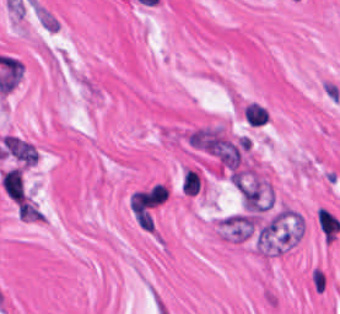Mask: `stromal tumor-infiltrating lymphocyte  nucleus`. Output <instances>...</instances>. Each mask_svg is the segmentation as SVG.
<instances>
[{
	"label": "stromal tumor-infiltrating lymphocyte nucleus",
	"instance_id": "stromal-tumor-infiltrating-lymphocyte-nucleus-1",
	"mask_svg": "<svg viewBox=\"0 0 340 314\" xmlns=\"http://www.w3.org/2000/svg\"><path fill=\"white\" fill-rule=\"evenodd\" d=\"M0 186L7 199L17 201L27 195L23 171L17 164L7 167L1 172Z\"/></svg>",
	"mask_w": 340,
	"mask_h": 314
},
{
	"label": "stromal tumor-infiltrating lymphocyte nucleus",
	"instance_id": "stromal-tumor-infiltrating-lymphocyte-nucleus-2",
	"mask_svg": "<svg viewBox=\"0 0 340 314\" xmlns=\"http://www.w3.org/2000/svg\"><path fill=\"white\" fill-rule=\"evenodd\" d=\"M317 222L324 240L331 242L339 228L340 222L320 207L317 210Z\"/></svg>",
	"mask_w": 340,
	"mask_h": 314
},
{
	"label": "stromal tumor-infiltrating lymphocyte nucleus",
	"instance_id": "stromal-tumor-infiltrating-lymphocyte-nucleus-3",
	"mask_svg": "<svg viewBox=\"0 0 340 314\" xmlns=\"http://www.w3.org/2000/svg\"><path fill=\"white\" fill-rule=\"evenodd\" d=\"M242 113L248 125H261L268 120V112L265 107L253 101L244 104Z\"/></svg>",
	"mask_w": 340,
	"mask_h": 314
},
{
	"label": "stromal tumor-infiltrating lymphocyte nucleus",
	"instance_id": "stromal-tumor-infiltrating-lymphocyte-nucleus-4",
	"mask_svg": "<svg viewBox=\"0 0 340 314\" xmlns=\"http://www.w3.org/2000/svg\"><path fill=\"white\" fill-rule=\"evenodd\" d=\"M310 286L317 292H323L326 288L328 274L322 265H313L309 274Z\"/></svg>",
	"mask_w": 340,
	"mask_h": 314
}]
</instances>
